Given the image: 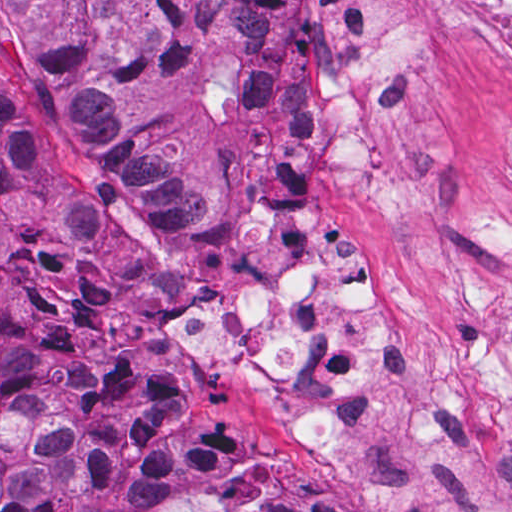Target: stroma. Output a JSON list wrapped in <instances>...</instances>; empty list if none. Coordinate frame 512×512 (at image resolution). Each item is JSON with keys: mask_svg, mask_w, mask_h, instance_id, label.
<instances>
[{"mask_svg": "<svg viewBox=\"0 0 512 512\" xmlns=\"http://www.w3.org/2000/svg\"><path fill=\"white\" fill-rule=\"evenodd\" d=\"M320 0H288L281 28L282 139L225 184L217 221L144 218L86 162L34 103L0 41V112L22 120L26 175L0 204V255L30 233H104L129 307L145 323L162 373L232 427L227 454L184 479L160 471L87 485L103 446L54 389L45 337L29 322L14 274L0 262V326L23 350L27 386L91 452L77 499L113 512L131 484H152L220 512L267 503L299 478L349 512H512V408L482 453L422 440L403 419L373 431L364 457L332 466L303 454L296 425L260 374L229 372L181 340L182 309L213 301L265 235L295 236L315 257L342 248L383 260L380 321L408 370L426 351L512 350V61L472 37L425 59L411 119L446 168L426 186L397 184L340 201L322 181L305 125L309 37ZM2 0H0L1 31Z\"/></svg>", "mask_w": 512, "mask_h": 512, "instance_id": "obj_1", "label": "stroma"}]
</instances>
